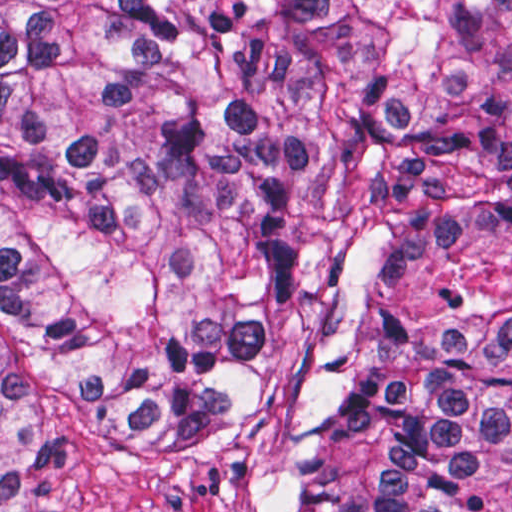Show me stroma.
Here are the masks:
<instances>
[{"label":"stroma","mask_w":512,"mask_h":512,"mask_svg":"<svg viewBox=\"0 0 512 512\" xmlns=\"http://www.w3.org/2000/svg\"><path fill=\"white\" fill-rule=\"evenodd\" d=\"M74 512H265L243 468L143 418L86 440L74 467Z\"/></svg>","instance_id":"stroma-1"}]
</instances>
